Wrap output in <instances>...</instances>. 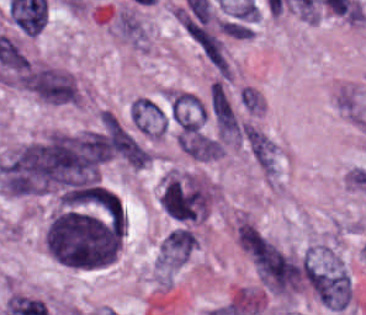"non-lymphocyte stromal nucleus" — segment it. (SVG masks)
<instances>
[{
  "instance_id": "dd21d789",
  "label": "non-lymphocyte stromal nucleus",
  "mask_w": 366,
  "mask_h": 315,
  "mask_svg": "<svg viewBox=\"0 0 366 315\" xmlns=\"http://www.w3.org/2000/svg\"><path fill=\"white\" fill-rule=\"evenodd\" d=\"M104 156L88 136H53L20 147L1 166L8 192L35 193L92 182Z\"/></svg>"
},
{
  "instance_id": "a72fc3eb",
  "label": "non-lymphocyte stromal nucleus",
  "mask_w": 366,
  "mask_h": 315,
  "mask_svg": "<svg viewBox=\"0 0 366 315\" xmlns=\"http://www.w3.org/2000/svg\"><path fill=\"white\" fill-rule=\"evenodd\" d=\"M25 88L54 104L77 102V87L72 78L56 70L32 66L22 77Z\"/></svg>"
},
{
  "instance_id": "3746e769",
  "label": "non-lymphocyte stromal nucleus",
  "mask_w": 366,
  "mask_h": 315,
  "mask_svg": "<svg viewBox=\"0 0 366 315\" xmlns=\"http://www.w3.org/2000/svg\"><path fill=\"white\" fill-rule=\"evenodd\" d=\"M102 146L108 157L131 167H142L147 160L142 148L110 118L102 120Z\"/></svg>"
},
{
  "instance_id": "fc2b8d12",
  "label": "non-lymphocyte stromal nucleus",
  "mask_w": 366,
  "mask_h": 315,
  "mask_svg": "<svg viewBox=\"0 0 366 315\" xmlns=\"http://www.w3.org/2000/svg\"><path fill=\"white\" fill-rule=\"evenodd\" d=\"M245 137L251 156L268 179H274L278 172V150L274 139L258 125H245Z\"/></svg>"
},
{
  "instance_id": "81446118",
  "label": "non-lymphocyte stromal nucleus",
  "mask_w": 366,
  "mask_h": 315,
  "mask_svg": "<svg viewBox=\"0 0 366 315\" xmlns=\"http://www.w3.org/2000/svg\"><path fill=\"white\" fill-rule=\"evenodd\" d=\"M130 119L146 135L161 136L167 127L163 110L150 99L136 98L130 107Z\"/></svg>"
},
{
  "instance_id": "7c5642bf",
  "label": "non-lymphocyte stromal nucleus",
  "mask_w": 366,
  "mask_h": 315,
  "mask_svg": "<svg viewBox=\"0 0 366 315\" xmlns=\"http://www.w3.org/2000/svg\"><path fill=\"white\" fill-rule=\"evenodd\" d=\"M178 146L196 160L210 161L223 156V145L201 134L178 135Z\"/></svg>"
},
{
  "instance_id": "9d01c50a",
  "label": "non-lymphocyte stromal nucleus",
  "mask_w": 366,
  "mask_h": 315,
  "mask_svg": "<svg viewBox=\"0 0 366 315\" xmlns=\"http://www.w3.org/2000/svg\"><path fill=\"white\" fill-rule=\"evenodd\" d=\"M335 106L352 122L359 126H366V112L358 90L353 85H343L336 94Z\"/></svg>"
},
{
  "instance_id": "2ac0efb1",
  "label": "non-lymphocyte stromal nucleus",
  "mask_w": 366,
  "mask_h": 315,
  "mask_svg": "<svg viewBox=\"0 0 366 315\" xmlns=\"http://www.w3.org/2000/svg\"><path fill=\"white\" fill-rule=\"evenodd\" d=\"M210 101L219 125L234 126L231 106L221 85L216 81L211 86Z\"/></svg>"
}]
</instances>
